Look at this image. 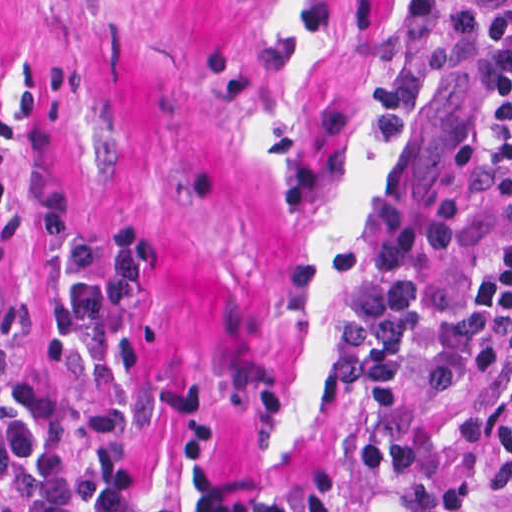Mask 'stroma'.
Masks as SVG:
<instances>
[{"label":"stroma","mask_w":512,"mask_h":512,"mask_svg":"<svg viewBox=\"0 0 512 512\" xmlns=\"http://www.w3.org/2000/svg\"><path fill=\"white\" fill-rule=\"evenodd\" d=\"M498 142L440 0H0V388L47 387L79 454L107 407L145 492L166 427L40 319L63 210L158 256L118 344L132 385L208 386L239 483L346 512H445L435 429L512 370L423 386L410 341L501 230Z\"/></svg>","instance_id":"1"}]
</instances>
